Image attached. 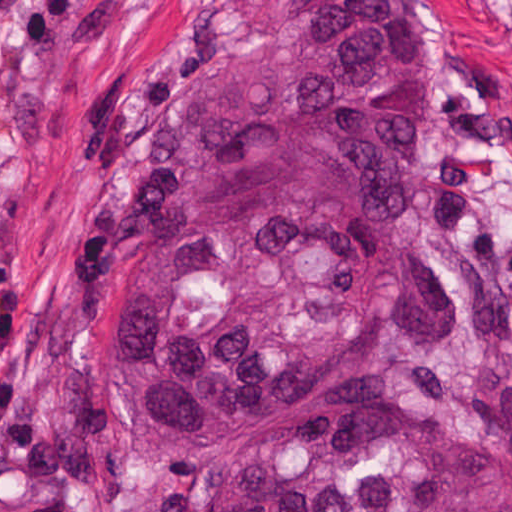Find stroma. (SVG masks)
I'll return each mask as SVG.
<instances>
[{"label":"stroma","mask_w":512,"mask_h":512,"mask_svg":"<svg viewBox=\"0 0 512 512\" xmlns=\"http://www.w3.org/2000/svg\"><path fill=\"white\" fill-rule=\"evenodd\" d=\"M441 43L414 162L458 327L396 347L395 387L512 440V0H410ZM319 0H0V512H168L123 426L118 329L87 295L105 199L157 110Z\"/></svg>","instance_id":"obj_1"}]
</instances>
